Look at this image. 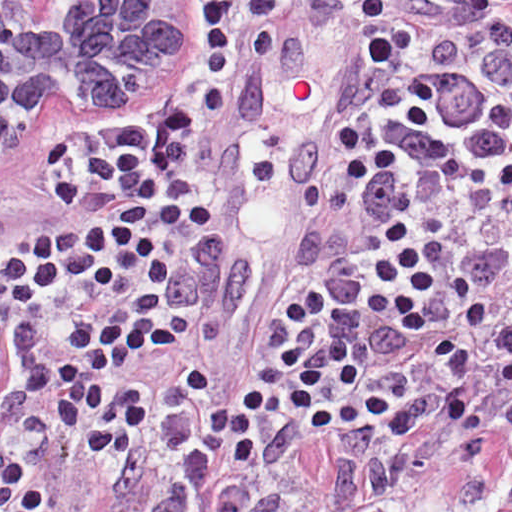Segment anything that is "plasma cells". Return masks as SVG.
Returning <instances> with one entry per match:
<instances>
[{
    "instance_id": "obj_1",
    "label": "plasma cells",
    "mask_w": 512,
    "mask_h": 512,
    "mask_svg": "<svg viewBox=\"0 0 512 512\" xmlns=\"http://www.w3.org/2000/svg\"><path fill=\"white\" fill-rule=\"evenodd\" d=\"M382 115L420 134H439L458 143L454 152L428 140H398L400 150L431 169L454 191L500 201L512 228V75L500 95L474 77L450 38L432 35L423 43L422 62L404 83L382 88ZM512 279V245L497 241L458 258L448 281L458 313L470 335L485 327L490 296ZM431 350L444 370L439 389L426 390L399 404L380 394H366L361 404L382 440L401 446L419 424L459 429L435 441L460 464L512 470V404L489 415L474 404L468 384L493 381L512 387V326L494 338L490 363L477 369L468 349L447 338L432 339ZM357 512H395L381 502Z\"/></svg>"
}]
</instances>
